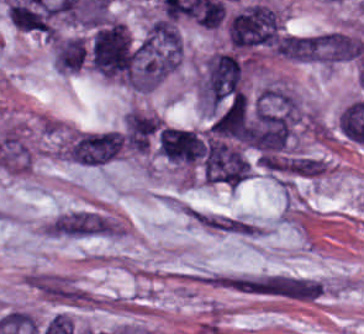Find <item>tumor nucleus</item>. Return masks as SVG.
<instances>
[{
	"label": "tumor nucleus",
	"mask_w": 364,
	"mask_h": 334,
	"mask_svg": "<svg viewBox=\"0 0 364 334\" xmlns=\"http://www.w3.org/2000/svg\"><path fill=\"white\" fill-rule=\"evenodd\" d=\"M200 169L211 184L236 187L249 178L251 163L239 140L212 127L199 134Z\"/></svg>",
	"instance_id": "2f306a5c"
},
{
	"label": "tumor nucleus",
	"mask_w": 364,
	"mask_h": 334,
	"mask_svg": "<svg viewBox=\"0 0 364 334\" xmlns=\"http://www.w3.org/2000/svg\"><path fill=\"white\" fill-rule=\"evenodd\" d=\"M158 153L170 162L193 166L201 158L200 138L187 129L163 126L158 133Z\"/></svg>",
	"instance_id": "8643909e"
},
{
	"label": "tumor nucleus",
	"mask_w": 364,
	"mask_h": 334,
	"mask_svg": "<svg viewBox=\"0 0 364 334\" xmlns=\"http://www.w3.org/2000/svg\"><path fill=\"white\" fill-rule=\"evenodd\" d=\"M85 60L84 39L82 36H69L58 39L53 45L52 64L59 73H75Z\"/></svg>",
	"instance_id": "5ab6c2c4"
}]
</instances>
